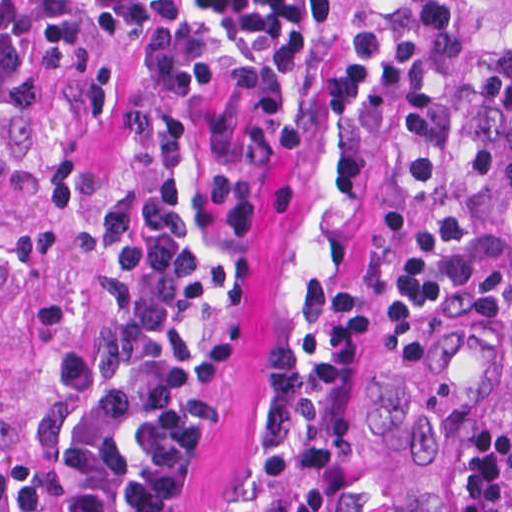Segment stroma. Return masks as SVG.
<instances>
[{
	"instance_id": "stroma-1",
	"label": "stroma",
	"mask_w": 512,
	"mask_h": 512,
	"mask_svg": "<svg viewBox=\"0 0 512 512\" xmlns=\"http://www.w3.org/2000/svg\"><path fill=\"white\" fill-rule=\"evenodd\" d=\"M352 42L370 30L396 41L393 79L356 114L321 106L330 47L297 82L310 143L295 162L265 159L259 143L263 78L241 48L204 30L211 83L157 92L145 56L80 34L86 56L28 88L0 80V512L14 463L34 457V434L58 391L59 371L114 328L103 273L123 271L118 251L135 235L141 203L160 175L173 179L177 213L208 295L198 339L235 332L227 403L196 475L194 512H288L291 494L265 483L263 460L281 436L267 425L272 351L319 364L334 301L370 298L371 331L383 308L367 235L378 153L372 112L410 80L449 36L445 0H347ZM153 410L121 434L110 512H128L141 432ZM348 472L330 512H341L350 477L365 472L369 409L358 383Z\"/></svg>"
}]
</instances>
